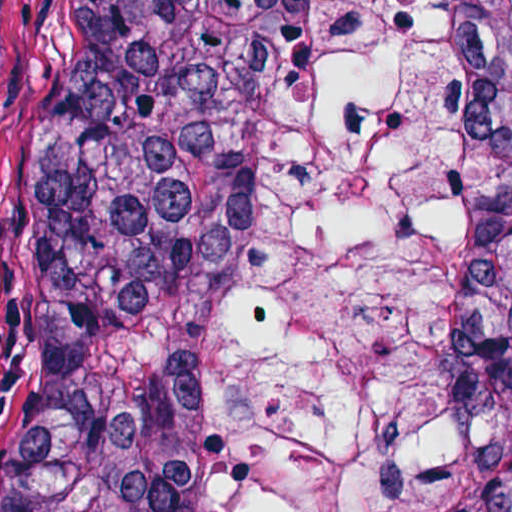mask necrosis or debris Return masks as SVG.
<instances>
[{"label": "necrosis or debris", "instance_id": "necrosis-or-debris-1", "mask_svg": "<svg viewBox=\"0 0 512 512\" xmlns=\"http://www.w3.org/2000/svg\"><path fill=\"white\" fill-rule=\"evenodd\" d=\"M499 458L456 350V53L439 0H323L218 512H467Z\"/></svg>", "mask_w": 512, "mask_h": 512}]
</instances>
